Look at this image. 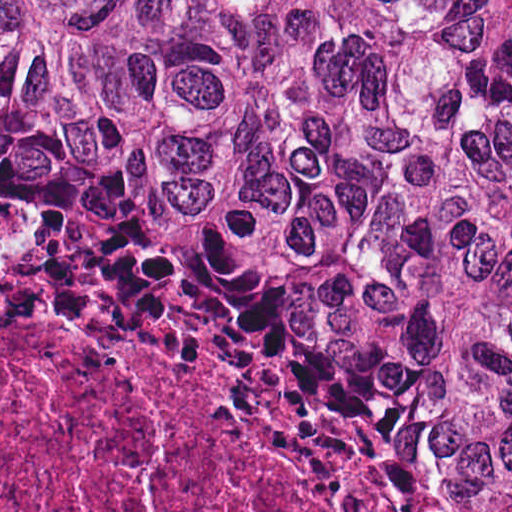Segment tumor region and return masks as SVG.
<instances>
[{
	"label": "tumor region",
	"instance_id": "1",
	"mask_svg": "<svg viewBox=\"0 0 512 512\" xmlns=\"http://www.w3.org/2000/svg\"><path fill=\"white\" fill-rule=\"evenodd\" d=\"M0 281L328 505L512 512V0H0Z\"/></svg>",
	"mask_w": 512,
	"mask_h": 512
}]
</instances>
